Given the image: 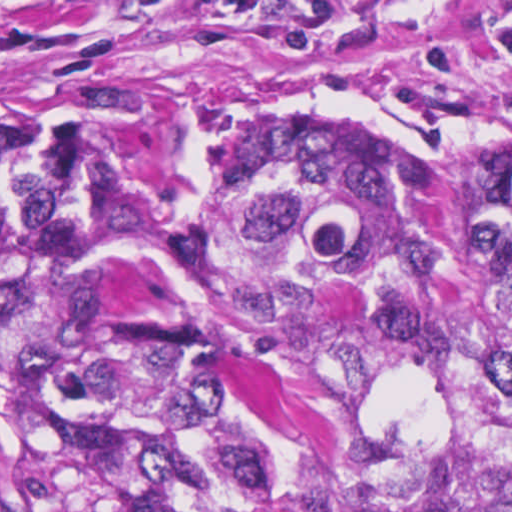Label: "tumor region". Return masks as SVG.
Listing matches in <instances>:
<instances>
[{
	"label": "tumor region",
	"instance_id": "tumor-region-1",
	"mask_svg": "<svg viewBox=\"0 0 512 512\" xmlns=\"http://www.w3.org/2000/svg\"><path fill=\"white\" fill-rule=\"evenodd\" d=\"M212 276L296 386L300 452L213 434ZM1 396L42 512H512V192L259 134L135 203L1 126Z\"/></svg>",
	"mask_w": 512,
	"mask_h": 512
}]
</instances>
